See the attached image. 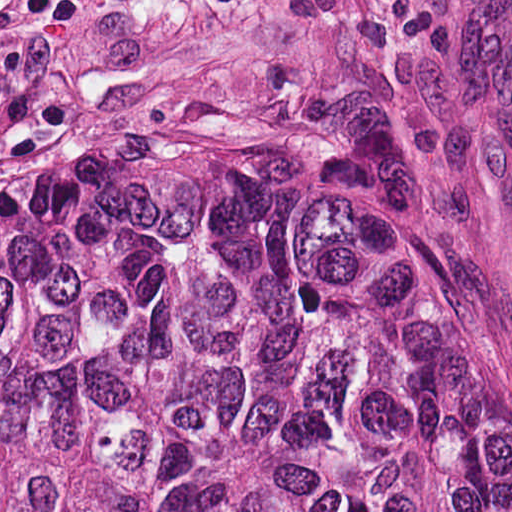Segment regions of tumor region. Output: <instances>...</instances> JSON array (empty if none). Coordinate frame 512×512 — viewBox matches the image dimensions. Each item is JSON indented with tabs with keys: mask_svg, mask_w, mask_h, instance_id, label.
Returning a JSON list of instances; mask_svg holds the SVG:
<instances>
[{
	"mask_svg": "<svg viewBox=\"0 0 512 512\" xmlns=\"http://www.w3.org/2000/svg\"><path fill=\"white\" fill-rule=\"evenodd\" d=\"M0 512H512L505 352L337 152L85 128L0 178Z\"/></svg>",
	"mask_w": 512,
	"mask_h": 512,
	"instance_id": "obj_1",
	"label": "tumor region"
}]
</instances>
